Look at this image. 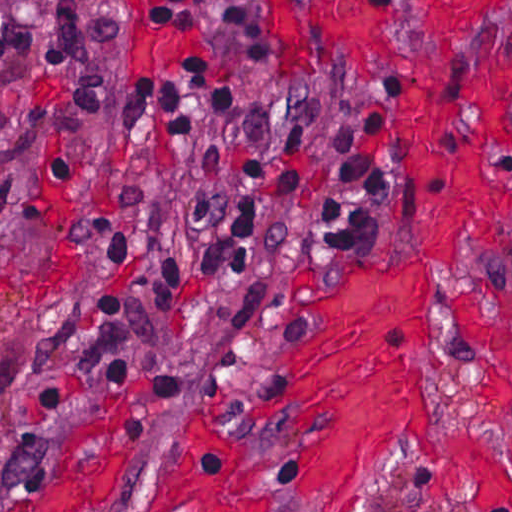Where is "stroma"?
Here are the masks:
<instances>
[{
	"instance_id": "obj_1",
	"label": "stroma",
	"mask_w": 512,
	"mask_h": 512,
	"mask_svg": "<svg viewBox=\"0 0 512 512\" xmlns=\"http://www.w3.org/2000/svg\"><path fill=\"white\" fill-rule=\"evenodd\" d=\"M461 4L476 21L443 40L426 34L427 1L404 0L384 53L321 63L268 49L256 0H210L215 63L206 19L195 58L142 75V0H0V25L58 22L87 69L58 117L40 275L13 321L18 385L0 423V471L36 472L8 512H172L159 492L177 438L206 424L227 435L232 469L252 494L246 512H336L299 482L308 415L259 410L292 386V341L324 328L293 307L298 298L332 290L368 262L428 261L440 278L441 365L414 350L440 433L470 435L512 479L507 424L447 311L468 293L512 290V212L497 209L467 228L456 265L425 260L390 108L396 70L434 61L486 71L492 97L512 115V0ZM199 66L241 94L238 112L208 118L194 139L162 131L154 109L127 117V90H160ZM349 151L368 155L375 174L372 228L292 245L285 262H265L199 305L183 359L153 377L133 372L152 264L208 235L241 188ZM481 164L485 175L512 179V151L485 148ZM435 470L417 449L392 452L374 464L359 512H477L439 502Z\"/></svg>"
}]
</instances>
